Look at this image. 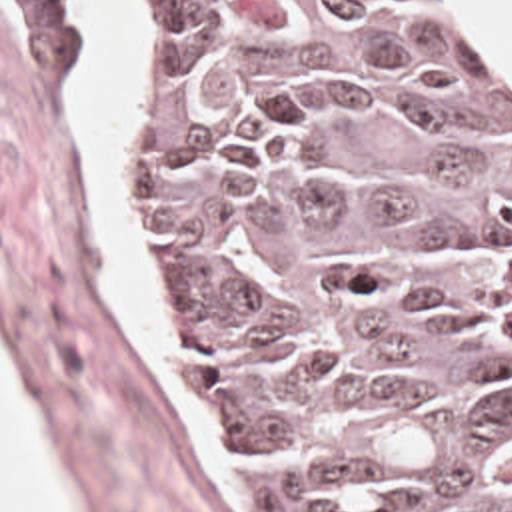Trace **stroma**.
I'll return each mask as SVG.
<instances>
[{"mask_svg": "<svg viewBox=\"0 0 512 512\" xmlns=\"http://www.w3.org/2000/svg\"><path fill=\"white\" fill-rule=\"evenodd\" d=\"M472 4L512 62L484 0ZM116 8L134 166V28L126 0ZM90 48L68 0H0V376L70 512H244L166 328L164 354L212 471L108 256L92 156L72 112ZM138 206L164 318L162 250L140 188Z\"/></svg>", "mask_w": 512, "mask_h": 512, "instance_id": "stroma-1", "label": "stroma"}]
</instances>
